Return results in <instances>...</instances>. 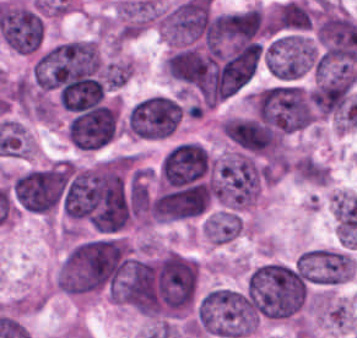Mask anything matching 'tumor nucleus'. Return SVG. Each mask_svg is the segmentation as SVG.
Segmentation results:
<instances>
[{
    "mask_svg": "<svg viewBox=\"0 0 357 338\" xmlns=\"http://www.w3.org/2000/svg\"><path fill=\"white\" fill-rule=\"evenodd\" d=\"M305 279L296 260H266L243 275L238 293L256 322L287 319L299 308Z\"/></svg>",
    "mask_w": 357,
    "mask_h": 338,
    "instance_id": "1",
    "label": "tumor nucleus"
},
{
    "mask_svg": "<svg viewBox=\"0 0 357 338\" xmlns=\"http://www.w3.org/2000/svg\"><path fill=\"white\" fill-rule=\"evenodd\" d=\"M258 324L239 288L215 286L204 292L194 308L195 335L238 338L251 335Z\"/></svg>",
    "mask_w": 357,
    "mask_h": 338,
    "instance_id": "2",
    "label": "tumor nucleus"
},
{
    "mask_svg": "<svg viewBox=\"0 0 357 338\" xmlns=\"http://www.w3.org/2000/svg\"><path fill=\"white\" fill-rule=\"evenodd\" d=\"M184 105L173 93H147L137 98L123 115V130L130 136L156 139L176 130Z\"/></svg>",
    "mask_w": 357,
    "mask_h": 338,
    "instance_id": "3",
    "label": "tumor nucleus"
},
{
    "mask_svg": "<svg viewBox=\"0 0 357 338\" xmlns=\"http://www.w3.org/2000/svg\"><path fill=\"white\" fill-rule=\"evenodd\" d=\"M316 62L313 38L298 29L275 33L264 44V70L282 81H293L312 72Z\"/></svg>",
    "mask_w": 357,
    "mask_h": 338,
    "instance_id": "4",
    "label": "tumor nucleus"
},
{
    "mask_svg": "<svg viewBox=\"0 0 357 338\" xmlns=\"http://www.w3.org/2000/svg\"><path fill=\"white\" fill-rule=\"evenodd\" d=\"M353 257L344 247L303 250L302 274L314 285L335 286L352 278Z\"/></svg>",
    "mask_w": 357,
    "mask_h": 338,
    "instance_id": "5",
    "label": "tumor nucleus"
},
{
    "mask_svg": "<svg viewBox=\"0 0 357 338\" xmlns=\"http://www.w3.org/2000/svg\"><path fill=\"white\" fill-rule=\"evenodd\" d=\"M242 232V216L235 211L211 210L204 216L201 234L206 242L228 244Z\"/></svg>",
    "mask_w": 357,
    "mask_h": 338,
    "instance_id": "6",
    "label": "tumor nucleus"
}]
</instances>
